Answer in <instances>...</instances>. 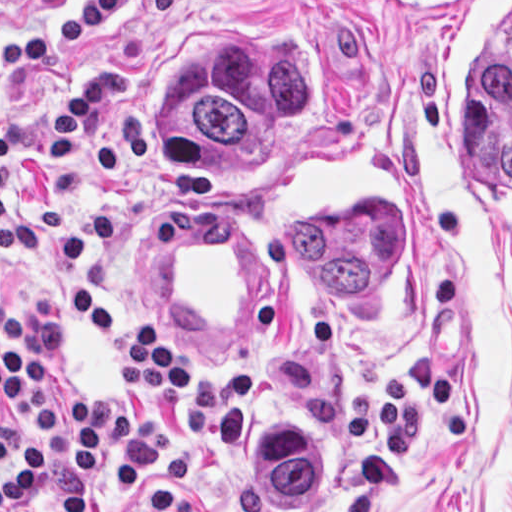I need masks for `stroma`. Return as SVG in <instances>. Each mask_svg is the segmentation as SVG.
Segmentation results:
<instances>
[{
	"mask_svg": "<svg viewBox=\"0 0 512 512\" xmlns=\"http://www.w3.org/2000/svg\"><path fill=\"white\" fill-rule=\"evenodd\" d=\"M449 1L0 0V512L16 416L1 404V352L44 349V404L121 402L106 344L76 330L64 296L89 291L110 315L149 323L189 353V385L149 403L173 425L170 458L125 491L105 464L85 512H512V230L447 211L424 186L415 133L433 43ZM240 40L318 52V96L228 170H166L152 86L171 62ZM127 73L124 99L93 108L79 146L103 143L134 110L152 146L124 185H102L47 147L53 118L93 72ZM345 138L378 148L415 190L434 275V336L413 365L354 375L297 290L255 209L262 176ZM215 188L249 217L274 261V305L257 335L205 337L152 304L139 280L142 210ZM240 414H316L333 436L338 475L316 500H258L227 481L222 429ZM73 457L52 425L39 480L4 512H52Z\"/></svg>",
	"mask_w": 512,
	"mask_h": 512,
	"instance_id": "35a3bbf8",
	"label": "stroma"
}]
</instances>
